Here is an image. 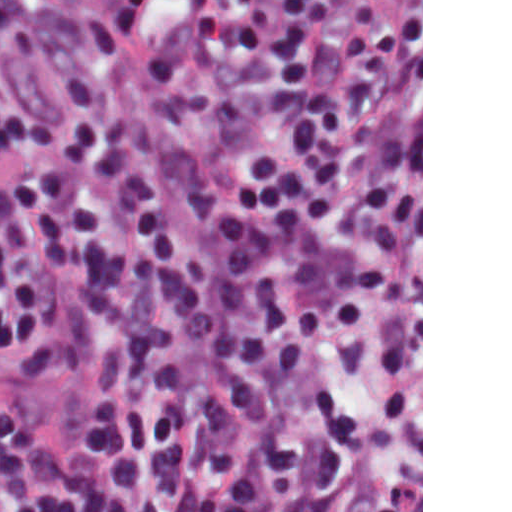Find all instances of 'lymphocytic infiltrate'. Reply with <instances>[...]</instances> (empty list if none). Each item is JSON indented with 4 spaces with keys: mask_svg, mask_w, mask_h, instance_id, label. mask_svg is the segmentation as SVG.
Returning <instances> with one entry per match:
<instances>
[{
    "mask_svg": "<svg viewBox=\"0 0 512 512\" xmlns=\"http://www.w3.org/2000/svg\"><path fill=\"white\" fill-rule=\"evenodd\" d=\"M205 180L128 125L0 101V487L13 512H368L382 450L388 75L329 0H93ZM18 13L0 0V34Z\"/></svg>",
    "mask_w": 512,
    "mask_h": 512,
    "instance_id": "obj_1",
    "label": "lymphocytic infiltrate"
}]
</instances>
